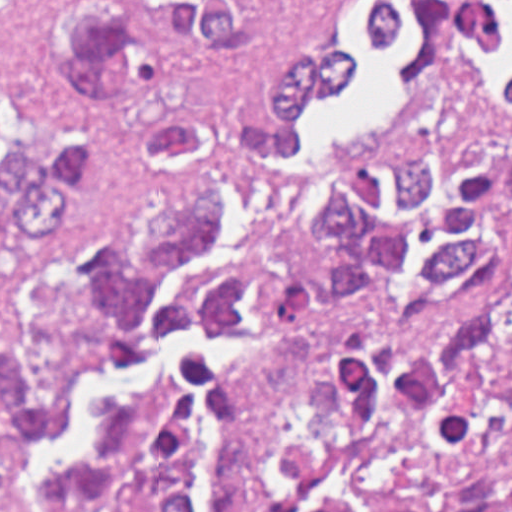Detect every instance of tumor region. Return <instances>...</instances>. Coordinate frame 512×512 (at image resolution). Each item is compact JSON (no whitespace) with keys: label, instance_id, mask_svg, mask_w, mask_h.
Wrapping results in <instances>:
<instances>
[{"label":"tumor region","instance_id":"tumor-region-1","mask_svg":"<svg viewBox=\"0 0 512 512\" xmlns=\"http://www.w3.org/2000/svg\"><path fill=\"white\" fill-rule=\"evenodd\" d=\"M271 13V1H262ZM38 27L80 93L59 123L0 61V269L75 218L90 197L101 97L120 101L151 156L211 131L167 82L178 46L217 58L257 38L261 1H39ZM363 55L283 45L238 85L232 151L204 185L113 238L67 246L33 270L21 329L0 346V512H21L19 476L56 432L76 377L130 365L169 328L242 334L235 371L188 356V389L164 383L103 423L87 458L58 469L32 512H189L203 440L200 397L218 406L213 512H233L261 389V328L315 338L343 391L325 433L280 422L252 512H512V134L400 142L363 170L309 179L290 209L293 238L261 291L249 274L180 284L142 330L138 311L216 225L212 193L252 183L278 197L302 168L254 157L296 146V115L335 92Z\"/></svg>","mask_w":512,"mask_h":512}]
</instances>
